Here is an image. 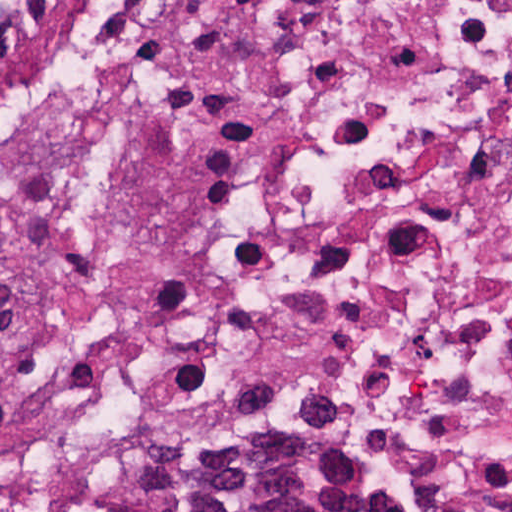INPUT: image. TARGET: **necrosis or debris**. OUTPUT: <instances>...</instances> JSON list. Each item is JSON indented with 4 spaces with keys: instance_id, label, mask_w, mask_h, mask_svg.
<instances>
[{
    "instance_id": "4bbe7bcc",
    "label": "necrosis or debris",
    "mask_w": 512,
    "mask_h": 512,
    "mask_svg": "<svg viewBox=\"0 0 512 512\" xmlns=\"http://www.w3.org/2000/svg\"><path fill=\"white\" fill-rule=\"evenodd\" d=\"M0 512H512V0H0Z\"/></svg>"
}]
</instances>
